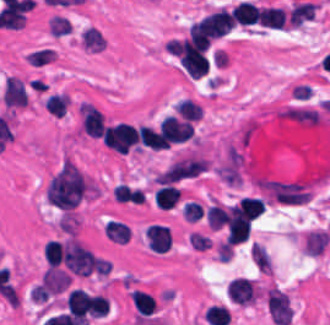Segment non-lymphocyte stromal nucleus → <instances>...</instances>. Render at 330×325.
<instances>
[{
	"label": "non-lymphocyte stromal nucleus",
	"instance_id": "fc2b8d12",
	"mask_svg": "<svg viewBox=\"0 0 330 325\" xmlns=\"http://www.w3.org/2000/svg\"><path fill=\"white\" fill-rule=\"evenodd\" d=\"M205 158L194 154H188L166 167L160 172L158 178L161 181H177L190 178L206 168Z\"/></svg>",
	"mask_w": 330,
	"mask_h": 325
},
{
	"label": "non-lymphocyte stromal nucleus",
	"instance_id": "dd21d789",
	"mask_svg": "<svg viewBox=\"0 0 330 325\" xmlns=\"http://www.w3.org/2000/svg\"><path fill=\"white\" fill-rule=\"evenodd\" d=\"M92 193V180L73 161L64 160L47 181L45 195L51 205L72 212Z\"/></svg>",
	"mask_w": 330,
	"mask_h": 325
},
{
	"label": "non-lymphocyte stromal nucleus",
	"instance_id": "a72fc3eb",
	"mask_svg": "<svg viewBox=\"0 0 330 325\" xmlns=\"http://www.w3.org/2000/svg\"><path fill=\"white\" fill-rule=\"evenodd\" d=\"M63 260L76 275L98 271V257L76 237H69L64 245Z\"/></svg>",
	"mask_w": 330,
	"mask_h": 325
},
{
	"label": "non-lymphocyte stromal nucleus",
	"instance_id": "3746e769",
	"mask_svg": "<svg viewBox=\"0 0 330 325\" xmlns=\"http://www.w3.org/2000/svg\"><path fill=\"white\" fill-rule=\"evenodd\" d=\"M266 194L277 204L299 205L309 199L310 193L297 180L263 179Z\"/></svg>",
	"mask_w": 330,
	"mask_h": 325
}]
</instances>
